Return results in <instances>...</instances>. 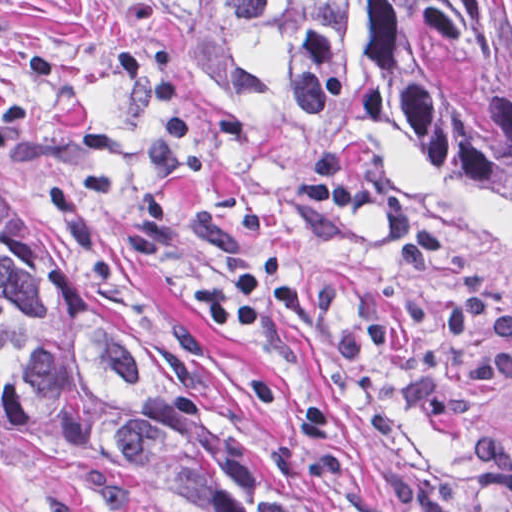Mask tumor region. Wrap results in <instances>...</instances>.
<instances>
[{
	"label": "tumor region",
	"mask_w": 512,
	"mask_h": 512,
	"mask_svg": "<svg viewBox=\"0 0 512 512\" xmlns=\"http://www.w3.org/2000/svg\"><path fill=\"white\" fill-rule=\"evenodd\" d=\"M255 90L454 164L512 219V0H92ZM0 419L206 512H322L223 415L147 297L0 174Z\"/></svg>",
	"instance_id": "tumor-region-1"
}]
</instances>
